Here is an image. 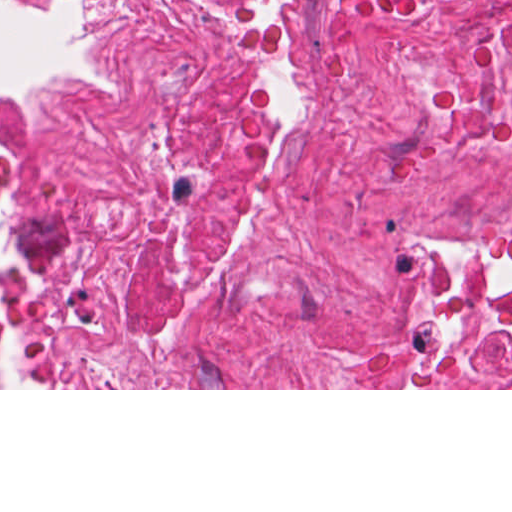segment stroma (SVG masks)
Returning <instances> with one entry per match:
<instances>
[{
    "label": "stroma",
    "mask_w": 512,
    "mask_h": 512,
    "mask_svg": "<svg viewBox=\"0 0 512 512\" xmlns=\"http://www.w3.org/2000/svg\"><path fill=\"white\" fill-rule=\"evenodd\" d=\"M23 16L39 14L58 4L73 10L78 39L84 51L93 18V0H4ZM70 75L48 78L34 83L0 90V106L33 101ZM0 390H512L509 388H0Z\"/></svg>",
    "instance_id": "35a3bbf8"
}]
</instances>
